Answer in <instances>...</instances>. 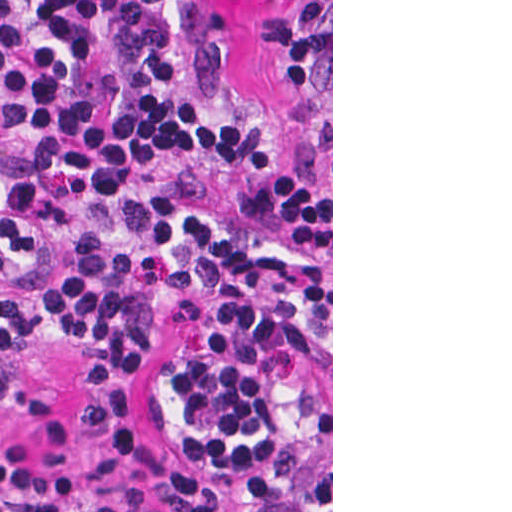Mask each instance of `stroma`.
<instances>
[{"mask_svg": "<svg viewBox=\"0 0 512 512\" xmlns=\"http://www.w3.org/2000/svg\"><path fill=\"white\" fill-rule=\"evenodd\" d=\"M272 0H217L225 54L247 113L272 114L281 104L279 44ZM215 294L197 298L148 341L137 388L144 429L178 459L210 458L191 441L169 393V376ZM283 311V459L298 512H333V0H331V309ZM106 336L84 332L52 339L22 359L0 362V378L18 375L48 384L58 415L80 417L86 379Z\"/></svg>", "mask_w": 512, "mask_h": 512, "instance_id": "obj_1", "label": "stroma"}]
</instances>
